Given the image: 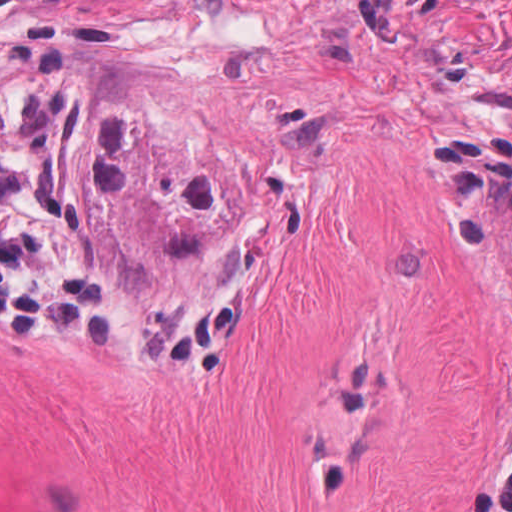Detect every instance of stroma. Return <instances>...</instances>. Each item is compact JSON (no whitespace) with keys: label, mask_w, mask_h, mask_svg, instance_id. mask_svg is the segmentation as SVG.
<instances>
[{"label":"stroma","mask_w":512,"mask_h":512,"mask_svg":"<svg viewBox=\"0 0 512 512\" xmlns=\"http://www.w3.org/2000/svg\"><path fill=\"white\" fill-rule=\"evenodd\" d=\"M67 72L113 289L242 299L220 379L0 341V512H470L512 427V0H0Z\"/></svg>","instance_id":"stroma-1"}]
</instances>
